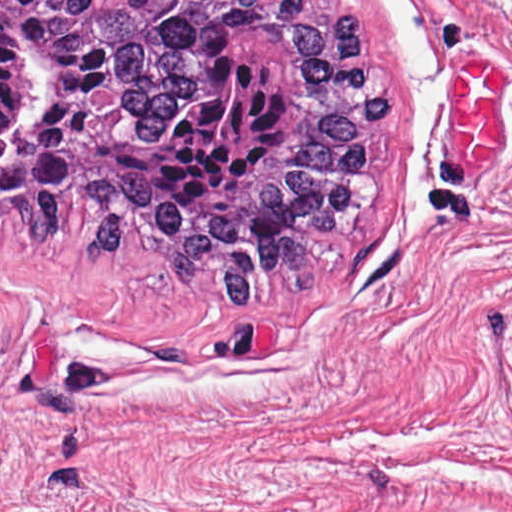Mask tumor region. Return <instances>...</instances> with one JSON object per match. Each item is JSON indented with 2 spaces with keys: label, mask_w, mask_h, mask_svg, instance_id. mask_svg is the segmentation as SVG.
I'll return each mask as SVG.
<instances>
[{
  "label": "tumor region",
  "mask_w": 512,
  "mask_h": 512,
  "mask_svg": "<svg viewBox=\"0 0 512 512\" xmlns=\"http://www.w3.org/2000/svg\"><path fill=\"white\" fill-rule=\"evenodd\" d=\"M386 92L361 10L0 0V225L72 212L242 305L297 290L379 201Z\"/></svg>",
  "instance_id": "1"
}]
</instances>
